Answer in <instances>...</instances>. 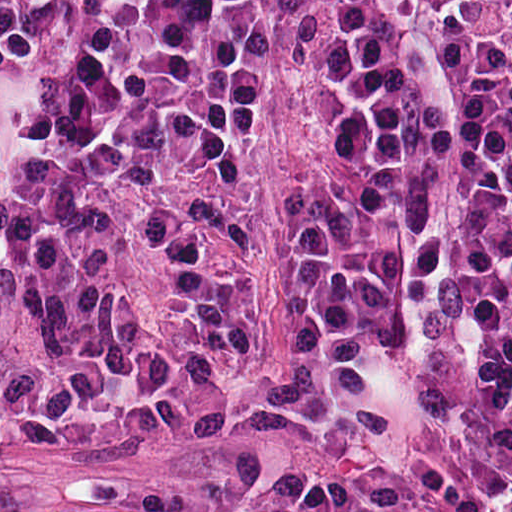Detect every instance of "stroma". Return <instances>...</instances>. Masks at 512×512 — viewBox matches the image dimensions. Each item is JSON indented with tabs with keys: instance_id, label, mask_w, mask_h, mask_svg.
<instances>
[{
	"instance_id": "1",
	"label": "stroma",
	"mask_w": 512,
	"mask_h": 512,
	"mask_svg": "<svg viewBox=\"0 0 512 512\" xmlns=\"http://www.w3.org/2000/svg\"><path fill=\"white\" fill-rule=\"evenodd\" d=\"M414 125L422 243L375 447L458 425L512 433L488 208L452 103L437 0H367ZM324 157L302 128L212 150L184 179L191 337L146 441L0 411V512H264L348 459L294 449V384Z\"/></svg>"
}]
</instances>
